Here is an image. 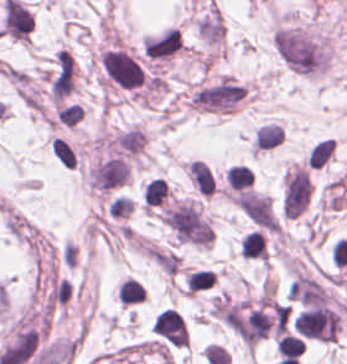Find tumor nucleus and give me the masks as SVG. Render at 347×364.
Wrapping results in <instances>:
<instances>
[{"label": "tumor nucleus", "mask_w": 347, "mask_h": 364, "mask_svg": "<svg viewBox=\"0 0 347 364\" xmlns=\"http://www.w3.org/2000/svg\"><path fill=\"white\" fill-rule=\"evenodd\" d=\"M272 44L282 65L293 75L317 76L329 64L331 41L327 34L294 25H281Z\"/></svg>", "instance_id": "1"}, {"label": "tumor nucleus", "mask_w": 347, "mask_h": 364, "mask_svg": "<svg viewBox=\"0 0 347 364\" xmlns=\"http://www.w3.org/2000/svg\"><path fill=\"white\" fill-rule=\"evenodd\" d=\"M186 177L199 195L212 196L217 191V183L210 166L200 159L190 161Z\"/></svg>", "instance_id": "2"}]
</instances>
